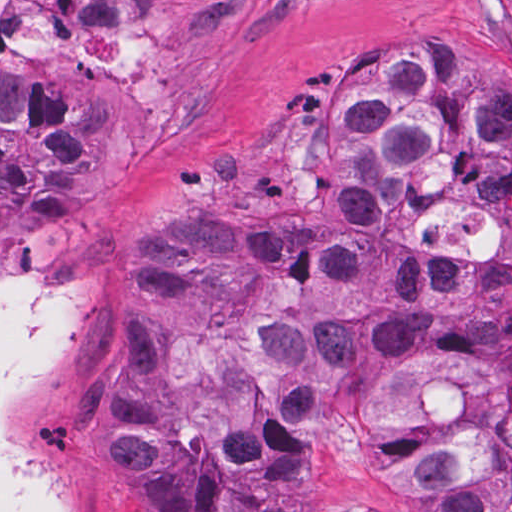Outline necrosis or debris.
Masks as SVG:
<instances>
[{"mask_svg": "<svg viewBox=\"0 0 512 512\" xmlns=\"http://www.w3.org/2000/svg\"><path fill=\"white\" fill-rule=\"evenodd\" d=\"M44 36L35 0H0V51L38 53Z\"/></svg>", "mask_w": 512, "mask_h": 512, "instance_id": "1", "label": "necrosis or debris"}]
</instances>
